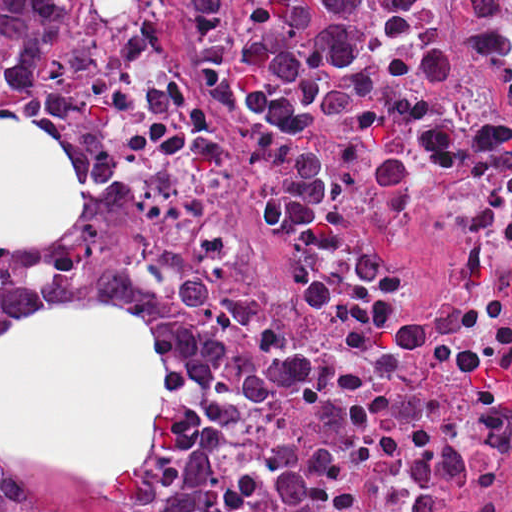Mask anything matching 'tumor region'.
Returning <instances> with one entry per match:
<instances>
[{
    "label": "tumor region",
    "mask_w": 512,
    "mask_h": 512,
    "mask_svg": "<svg viewBox=\"0 0 512 512\" xmlns=\"http://www.w3.org/2000/svg\"><path fill=\"white\" fill-rule=\"evenodd\" d=\"M234 0H196L187 45L192 70L228 107L285 139L289 165L260 197L267 233L313 240L330 213V170L311 124L340 113L382 81L427 77L446 59V31L430 0H266L233 29ZM78 0H0L7 83L28 99L49 92L66 63ZM53 294L106 297L134 306L164 341V414L134 476H80L31 460H0V476L33 469L52 477L129 486L160 473L182 445L187 399L200 370V321L168 275L136 262L74 256L0 260V336Z\"/></svg>",
    "instance_id": "1"
}]
</instances>
